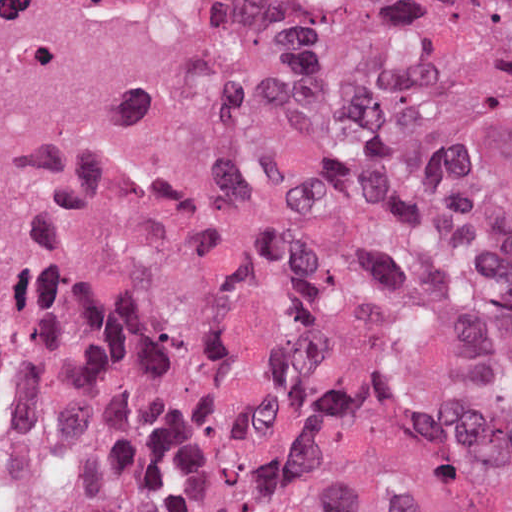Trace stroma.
I'll return each instance as SVG.
<instances>
[{
	"mask_svg": "<svg viewBox=\"0 0 512 512\" xmlns=\"http://www.w3.org/2000/svg\"><path fill=\"white\" fill-rule=\"evenodd\" d=\"M283 92H284V102H285L286 92L284 90H283ZM282 112H283V109L274 115H271L265 119L256 121V123L253 126V130H252L251 144L258 142V141H262V140L268 141L271 144L274 143V140H275V137H276L279 125H280ZM106 251L107 250L94 255L86 262L80 264L76 269H74L69 274V276L66 278L65 282L69 281L72 277H74L76 274H78L81 270H83L85 267H87L90 263H92L94 260H96L99 256H101ZM38 304H36V305H38ZM36 305L30 306V307L22 310L19 313V315L16 317L14 322H16L18 319H20L23 315H25L27 312H29ZM11 327H12V325H11ZM11 327L8 329L6 335L3 336L0 340H9Z\"/></svg>",
	"mask_w": 512,
	"mask_h": 512,
	"instance_id": "stroma-1",
	"label": "stroma"
}]
</instances>
